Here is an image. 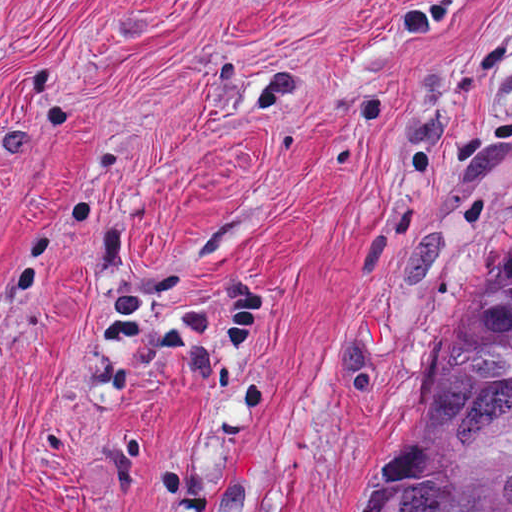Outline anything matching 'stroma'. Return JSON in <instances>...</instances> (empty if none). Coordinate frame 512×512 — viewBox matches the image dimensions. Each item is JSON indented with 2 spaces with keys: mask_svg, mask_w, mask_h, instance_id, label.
I'll return each mask as SVG.
<instances>
[{
  "mask_svg": "<svg viewBox=\"0 0 512 512\" xmlns=\"http://www.w3.org/2000/svg\"><path fill=\"white\" fill-rule=\"evenodd\" d=\"M512 282V0H0V512H364Z\"/></svg>",
  "mask_w": 512,
  "mask_h": 512,
  "instance_id": "35a3bbf8",
  "label": "stroma"
}]
</instances>
